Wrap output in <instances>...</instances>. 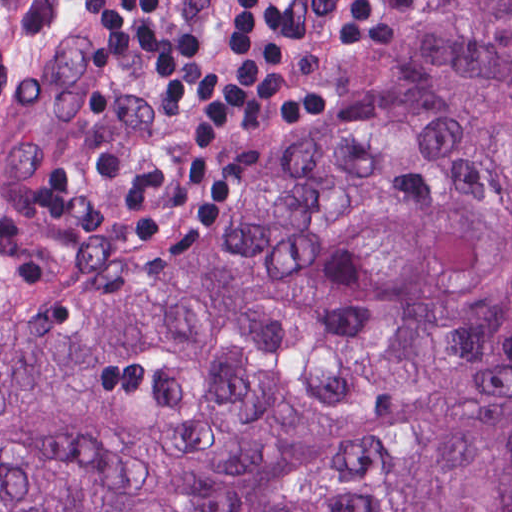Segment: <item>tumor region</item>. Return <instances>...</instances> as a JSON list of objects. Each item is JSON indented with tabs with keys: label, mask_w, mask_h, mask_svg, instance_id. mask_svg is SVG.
I'll return each mask as SVG.
<instances>
[{
	"label": "tumor region",
	"mask_w": 512,
	"mask_h": 512,
	"mask_svg": "<svg viewBox=\"0 0 512 512\" xmlns=\"http://www.w3.org/2000/svg\"><path fill=\"white\" fill-rule=\"evenodd\" d=\"M96 114L0 0V512H512V0H437L170 273L13 194Z\"/></svg>",
	"instance_id": "tumor-region-1"
}]
</instances>
